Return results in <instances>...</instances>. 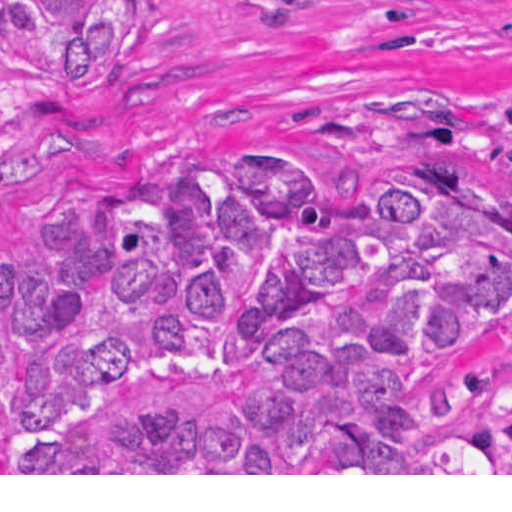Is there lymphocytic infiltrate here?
Instances as JSON below:
<instances>
[{"instance_id": "1", "label": "lymphocytic infiltrate", "mask_w": 512, "mask_h": 512, "mask_svg": "<svg viewBox=\"0 0 512 512\" xmlns=\"http://www.w3.org/2000/svg\"><path fill=\"white\" fill-rule=\"evenodd\" d=\"M488 123L493 127L509 134L504 122L497 114V100L488 109Z\"/></svg>"}]
</instances>
